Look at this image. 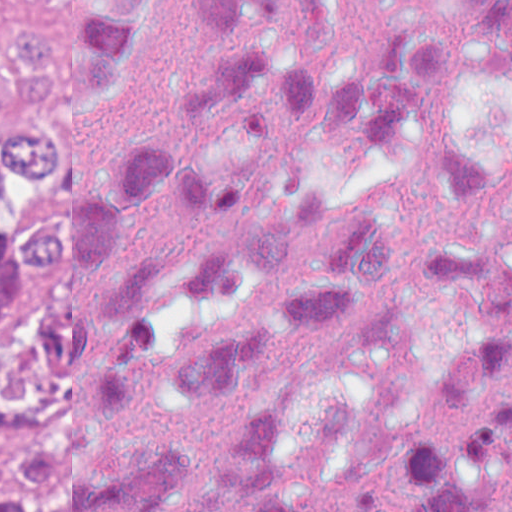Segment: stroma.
Wrapping results in <instances>:
<instances>
[{"instance_id":"stroma-1","label":"stroma","mask_w":512,"mask_h":512,"mask_svg":"<svg viewBox=\"0 0 512 512\" xmlns=\"http://www.w3.org/2000/svg\"><path fill=\"white\" fill-rule=\"evenodd\" d=\"M18 1H70V0H0V72L5 74V22L16 9ZM58 137L65 154V169L54 180L53 207L43 226L70 217V109H56ZM41 226V227H43ZM76 409V399L40 420L14 427L0 438V482L19 485L27 506L21 512H38L39 504L19 477L13 452L25 436L48 429Z\"/></svg>"}]
</instances>
